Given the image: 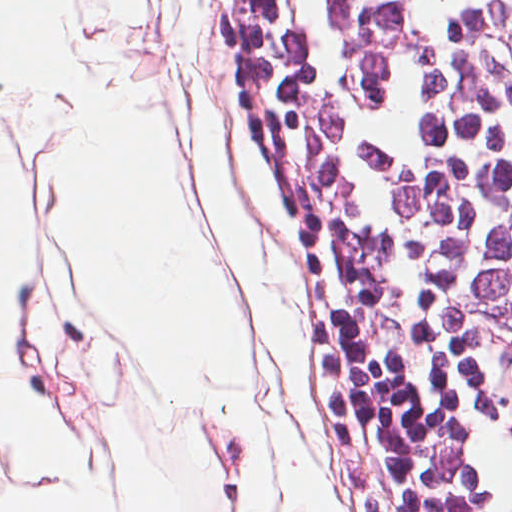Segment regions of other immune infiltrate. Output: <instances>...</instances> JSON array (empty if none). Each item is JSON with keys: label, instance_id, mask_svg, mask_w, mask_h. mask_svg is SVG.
<instances>
[{"label": "other immune infiltrate", "instance_id": "obj_1", "mask_svg": "<svg viewBox=\"0 0 512 512\" xmlns=\"http://www.w3.org/2000/svg\"><path fill=\"white\" fill-rule=\"evenodd\" d=\"M385 392L402 433L408 464L419 489L423 511L463 512L417 437L411 431L386 390Z\"/></svg>", "mask_w": 512, "mask_h": 512}]
</instances>
